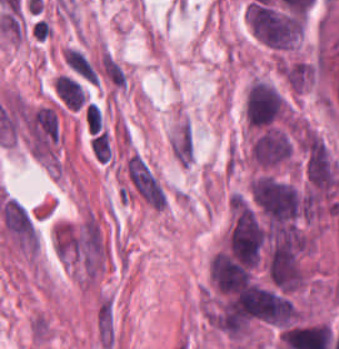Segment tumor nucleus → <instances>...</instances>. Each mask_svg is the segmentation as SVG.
<instances>
[{"label": "tumor nucleus", "mask_w": 339, "mask_h": 349, "mask_svg": "<svg viewBox=\"0 0 339 349\" xmlns=\"http://www.w3.org/2000/svg\"><path fill=\"white\" fill-rule=\"evenodd\" d=\"M243 113L250 127L260 129L288 119V103L271 83L255 79L247 88Z\"/></svg>", "instance_id": "tumor-nucleus-3"}, {"label": "tumor nucleus", "mask_w": 339, "mask_h": 349, "mask_svg": "<svg viewBox=\"0 0 339 349\" xmlns=\"http://www.w3.org/2000/svg\"><path fill=\"white\" fill-rule=\"evenodd\" d=\"M293 147V136L283 125L260 128L253 134L248 159L258 169L269 170L287 164Z\"/></svg>", "instance_id": "tumor-nucleus-4"}, {"label": "tumor nucleus", "mask_w": 339, "mask_h": 349, "mask_svg": "<svg viewBox=\"0 0 339 349\" xmlns=\"http://www.w3.org/2000/svg\"><path fill=\"white\" fill-rule=\"evenodd\" d=\"M282 71L287 83L297 91L312 86L318 76L317 65L312 60H286Z\"/></svg>", "instance_id": "tumor-nucleus-6"}, {"label": "tumor nucleus", "mask_w": 339, "mask_h": 349, "mask_svg": "<svg viewBox=\"0 0 339 349\" xmlns=\"http://www.w3.org/2000/svg\"><path fill=\"white\" fill-rule=\"evenodd\" d=\"M248 199L265 224L297 228L302 214L300 192L287 180L259 173L248 185Z\"/></svg>", "instance_id": "tumor-nucleus-1"}, {"label": "tumor nucleus", "mask_w": 339, "mask_h": 349, "mask_svg": "<svg viewBox=\"0 0 339 349\" xmlns=\"http://www.w3.org/2000/svg\"><path fill=\"white\" fill-rule=\"evenodd\" d=\"M245 17L253 37L273 50L295 46L300 38L303 14L250 0Z\"/></svg>", "instance_id": "tumor-nucleus-2"}, {"label": "tumor nucleus", "mask_w": 339, "mask_h": 349, "mask_svg": "<svg viewBox=\"0 0 339 349\" xmlns=\"http://www.w3.org/2000/svg\"><path fill=\"white\" fill-rule=\"evenodd\" d=\"M89 149L96 160H110L111 144L106 130L99 129L88 137Z\"/></svg>", "instance_id": "tumor-nucleus-8"}, {"label": "tumor nucleus", "mask_w": 339, "mask_h": 349, "mask_svg": "<svg viewBox=\"0 0 339 349\" xmlns=\"http://www.w3.org/2000/svg\"><path fill=\"white\" fill-rule=\"evenodd\" d=\"M209 275L220 293H234L253 284L248 265L220 250L209 262Z\"/></svg>", "instance_id": "tumor-nucleus-5"}, {"label": "tumor nucleus", "mask_w": 339, "mask_h": 349, "mask_svg": "<svg viewBox=\"0 0 339 349\" xmlns=\"http://www.w3.org/2000/svg\"><path fill=\"white\" fill-rule=\"evenodd\" d=\"M55 90L63 103L71 109L77 110L86 101L82 85L66 74L58 75L55 80Z\"/></svg>", "instance_id": "tumor-nucleus-7"}]
</instances>
